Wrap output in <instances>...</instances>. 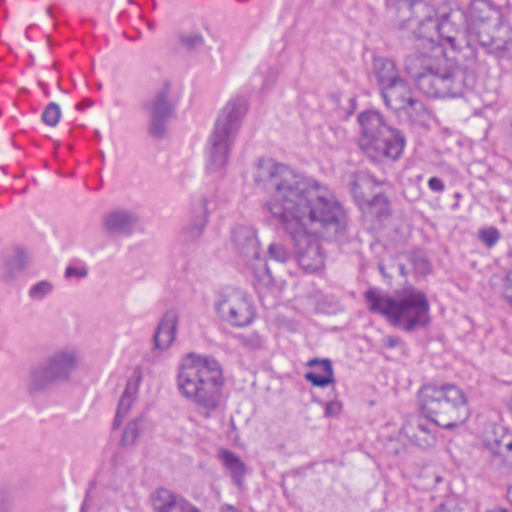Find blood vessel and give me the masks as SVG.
<instances>
[{"instance_id": "blood-vessel-1", "label": "blood vessel", "mask_w": 512, "mask_h": 512, "mask_svg": "<svg viewBox=\"0 0 512 512\" xmlns=\"http://www.w3.org/2000/svg\"><path fill=\"white\" fill-rule=\"evenodd\" d=\"M317 0H0V512H87Z\"/></svg>"}]
</instances>
